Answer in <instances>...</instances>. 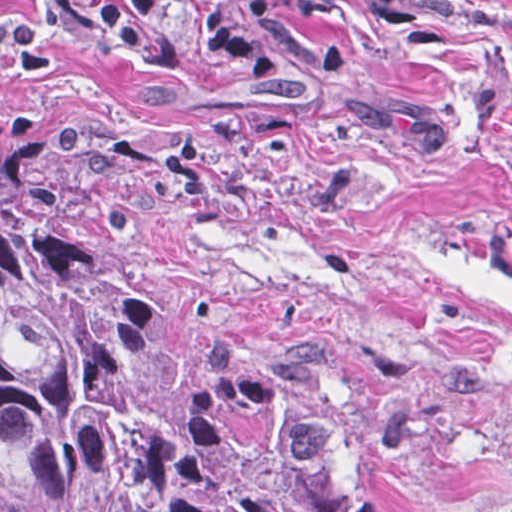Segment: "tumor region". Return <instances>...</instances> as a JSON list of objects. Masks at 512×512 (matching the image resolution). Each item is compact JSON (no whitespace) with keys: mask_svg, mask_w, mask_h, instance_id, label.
I'll return each instance as SVG.
<instances>
[{"mask_svg":"<svg viewBox=\"0 0 512 512\" xmlns=\"http://www.w3.org/2000/svg\"><path fill=\"white\" fill-rule=\"evenodd\" d=\"M350 368L316 334L207 344L196 369L75 174L0 145V489L23 512H317L298 431Z\"/></svg>","mask_w":512,"mask_h":512,"instance_id":"tumor-region-1","label":"tumor region"}]
</instances>
